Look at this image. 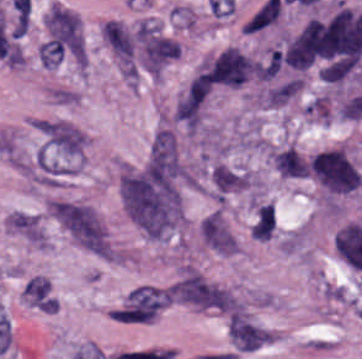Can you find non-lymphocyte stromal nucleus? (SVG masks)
<instances>
[{
	"label": "non-lymphocyte stromal nucleus",
	"mask_w": 362,
	"mask_h": 359,
	"mask_svg": "<svg viewBox=\"0 0 362 359\" xmlns=\"http://www.w3.org/2000/svg\"><path fill=\"white\" fill-rule=\"evenodd\" d=\"M119 192L130 220L150 238H163L181 217L178 179L146 163L122 168Z\"/></svg>",
	"instance_id": "obj_1"
},
{
	"label": "non-lymphocyte stromal nucleus",
	"mask_w": 362,
	"mask_h": 359,
	"mask_svg": "<svg viewBox=\"0 0 362 359\" xmlns=\"http://www.w3.org/2000/svg\"><path fill=\"white\" fill-rule=\"evenodd\" d=\"M44 21L59 32L86 66H93L90 59V18L85 12L66 1H55L43 6Z\"/></svg>",
	"instance_id": "obj_2"
},
{
	"label": "non-lymphocyte stromal nucleus",
	"mask_w": 362,
	"mask_h": 359,
	"mask_svg": "<svg viewBox=\"0 0 362 359\" xmlns=\"http://www.w3.org/2000/svg\"><path fill=\"white\" fill-rule=\"evenodd\" d=\"M58 222L84 248L108 255L109 246L105 227L99 214L83 203L58 202Z\"/></svg>",
	"instance_id": "obj_3"
},
{
	"label": "non-lymphocyte stromal nucleus",
	"mask_w": 362,
	"mask_h": 359,
	"mask_svg": "<svg viewBox=\"0 0 362 359\" xmlns=\"http://www.w3.org/2000/svg\"><path fill=\"white\" fill-rule=\"evenodd\" d=\"M172 297L178 303L227 310L230 292L195 269L188 268L175 283Z\"/></svg>",
	"instance_id": "obj_4"
},
{
	"label": "non-lymphocyte stromal nucleus",
	"mask_w": 362,
	"mask_h": 359,
	"mask_svg": "<svg viewBox=\"0 0 362 359\" xmlns=\"http://www.w3.org/2000/svg\"><path fill=\"white\" fill-rule=\"evenodd\" d=\"M101 37L126 77L135 78L139 67L136 25L111 19Z\"/></svg>",
	"instance_id": "obj_5"
},
{
	"label": "non-lymphocyte stromal nucleus",
	"mask_w": 362,
	"mask_h": 359,
	"mask_svg": "<svg viewBox=\"0 0 362 359\" xmlns=\"http://www.w3.org/2000/svg\"><path fill=\"white\" fill-rule=\"evenodd\" d=\"M147 162L152 171L175 182L184 174V166L178 149L176 138L169 129L156 132Z\"/></svg>",
	"instance_id": "obj_6"
},
{
	"label": "non-lymphocyte stromal nucleus",
	"mask_w": 362,
	"mask_h": 359,
	"mask_svg": "<svg viewBox=\"0 0 362 359\" xmlns=\"http://www.w3.org/2000/svg\"><path fill=\"white\" fill-rule=\"evenodd\" d=\"M46 147L59 156L78 157L84 149L85 138L72 124L60 121H43L37 126Z\"/></svg>",
	"instance_id": "obj_7"
},
{
	"label": "non-lymphocyte stromal nucleus",
	"mask_w": 362,
	"mask_h": 359,
	"mask_svg": "<svg viewBox=\"0 0 362 359\" xmlns=\"http://www.w3.org/2000/svg\"><path fill=\"white\" fill-rule=\"evenodd\" d=\"M209 94V84L195 76L178 100L174 115L188 131L199 126Z\"/></svg>",
	"instance_id": "obj_8"
},
{
	"label": "non-lymphocyte stromal nucleus",
	"mask_w": 362,
	"mask_h": 359,
	"mask_svg": "<svg viewBox=\"0 0 362 359\" xmlns=\"http://www.w3.org/2000/svg\"><path fill=\"white\" fill-rule=\"evenodd\" d=\"M204 243L220 254L234 252L233 236L220 211H213L200 224Z\"/></svg>",
	"instance_id": "obj_9"
},
{
	"label": "non-lymphocyte stromal nucleus",
	"mask_w": 362,
	"mask_h": 359,
	"mask_svg": "<svg viewBox=\"0 0 362 359\" xmlns=\"http://www.w3.org/2000/svg\"><path fill=\"white\" fill-rule=\"evenodd\" d=\"M210 180L217 195H226L246 186V174L227 164H219L210 172Z\"/></svg>",
	"instance_id": "obj_10"
}]
</instances>
